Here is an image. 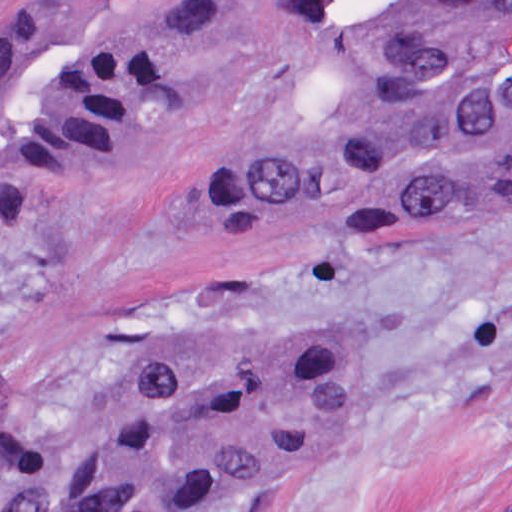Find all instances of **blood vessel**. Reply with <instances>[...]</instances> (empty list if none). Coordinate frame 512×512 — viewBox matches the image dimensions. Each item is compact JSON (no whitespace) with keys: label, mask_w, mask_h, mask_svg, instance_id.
Listing matches in <instances>:
<instances>
[{"label":"blood vessel","mask_w":512,"mask_h":512,"mask_svg":"<svg viewBox=\"0 0 512 512\" xmlns=\"http://www.w3.org/2000/svg\"><path fill=\"white\" fill-rule=\"evenodd\" d=\"M491 0H267L284 77L325 93L336 73L383 59L456 25Z\"/></svg>","instance_id":"blood-vessel-1"}]
</instances>
